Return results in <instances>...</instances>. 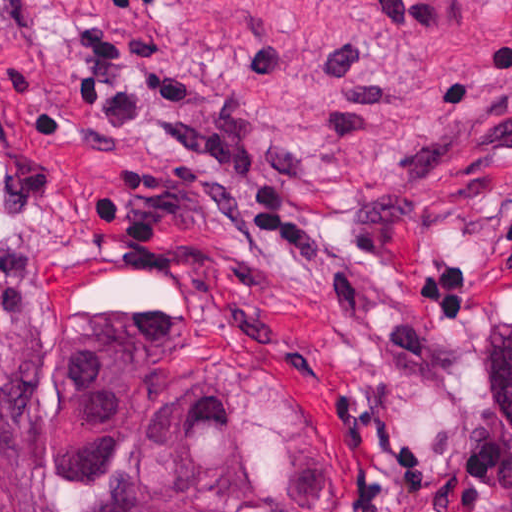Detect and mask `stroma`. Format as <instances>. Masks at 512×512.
<instances>
[{
	"instance_id": "obj_1",
	"label": "stroma",
	"mask_w": 512,
	"mask_h": 512,
	"mask_svg": "<svg viewBox=\"0 0 512 512\" xmlns=\"http://www.w3.org/2000/svg\"><path fill=\"white\" fill-rule=\"evenodd\" d=\"M224 398L294 512L512 491V0H0V443L55 363Z\"/></svg>"
}]
</instances>
